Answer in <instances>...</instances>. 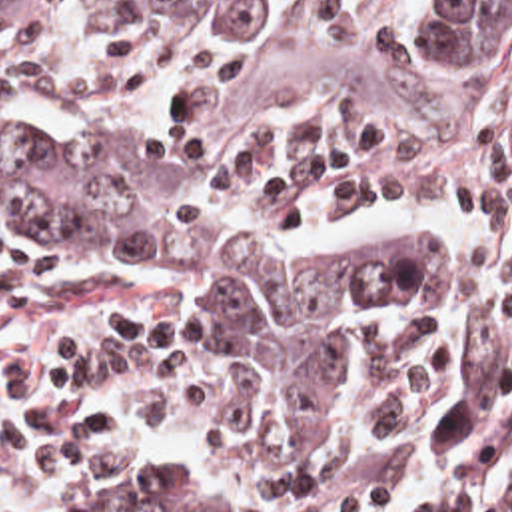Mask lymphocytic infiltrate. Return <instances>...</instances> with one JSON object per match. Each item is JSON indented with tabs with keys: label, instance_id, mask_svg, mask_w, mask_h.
I'll return each instance as SVG.
<instances>
[{
	"label": "lymphocytic infiltrate",
	"instance_id": "f902f5d3",
	"mask_svg": "<svg viewBox=\"0 0 512 512\" xmlns=\"http://www.w3.org/2000/svg\"><path fill=\"white\" fill-rule=\"evenodd\" d=\"M0 115L129 141L193 191L313 233L452 209L458 287L422 315L354 327L339 429L307 475L281 469L255 377L203 311H147L93 337L61 373L43 431V475L65 491L149 493L191 443L293 512H432L440 399L488 343L512 337V161L418 159L321 119L219 123L211 57L175 31L41 39L0 23ZM510 443L512 369L458 447V512ZM476 512H512V477Z\"/></svg>",
	"mask_w": 512,
	"mask_h": 512
}]
</instances>
